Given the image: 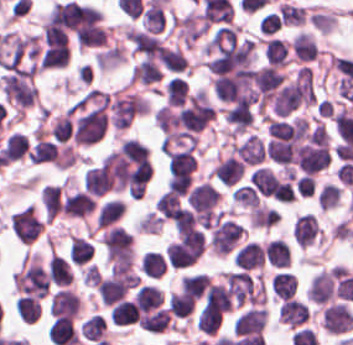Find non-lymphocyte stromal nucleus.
<instances>
[{
    "label": "non-lymphocyte stromal nucleus",
    "instance_id": "3746e769",
    "mask_svg": "<svg viewBox=\"0 0 353 345\" xmlns=\"http://www.w3.org/2000/svg\"><path fill=\"white\" fill-rule=\"evenodd\" d=\"M321 327L330 335H341L353 330V315L345 304H331L322 310Z\"/></svg>",
    "mask_w": 353,
    "mask_h": 345
},
{
    "label": "non-lymphocyte stromal nucleus",
    "instance_id": "68dcb563",
    "mask_svg": "<svg viewBox=\"0 0 353 345\" xmlns=\"http://www.w3.org/2000/svg\"><path fill=\"white\" fill-rule=\"evenodd\" d=\"M270 286L277 298L286 300L295 293L296 277L286 271H279L273 274Z\"/></svg>",
    "mask_w": 353,
    "mask_h": 345
},
{
    "label": "non-lymphocyte stromal nucleus",
    "instance_id": "8bb88acc",
    "mask_svg": "<svg viewBox=\"0 0 353 345\" xmlns=\"http://www.w3.org/2000/svg\"><path fill=\"white\" fill-rule=\"evenodd\" d=\"M109 321L117 326H126L137 322V309L130 299H123L114 305Z\"/></svg>",
    "mask_w": 353,
    "mask_h": 345
},
{
    "label": "non-lymphocyte stromal nucleus",
    "instance_id": "a72fc3eb",
    "mask_svg": "<svg viewBox=\"0 0 353 345\" xmlns=\"http://www.w3.org/2000/svg\"><path fill=\"white\" fill-rule=\"evenodd\" d=\"M14 236L21 243H32L40 234L42 220L35 206H27L10 217Z\"/></svg>",
    "mask_w": 353,
    "mask_h": 345
},
{
    "label": "non-lymphocyte stromal nucleus",
    "instance_id": "c95308c0",
    "mask_svg": "<svg viewBox=\"0 0 353 345\" xmlns=\"http://www.w3.org/2000/svg\"><path fill=\"white\" fill-rule=\"evenodd\" d=\"M208 281L209 276L202 273L185 274L181 278L180 289L197 300L207 288Z\"/></svg>",
    "mask_w": 353,
    "mask_h": 345
},
{
    "label": "non-lymphocyte stromal nucleus",
    "instance_id": "6412c185",
    "mask_svg": "<svg viewBox=\"0 0 353 345\" xmlns=\"http://www.w3.org/2000/svg\"><path fill=\"white\" fill-rule=\"evenodd\" d=\"M279 179L273 171L264 166H257L249 173V185L262 196H275Z\"/></svg>",
    "mask_w": 353,
    "mask_h": 345
},
{
    "label": "non-lymphocyte stromal nucleus",
    "instance_id": "0ceb972a",
    "mask_svg": "<svg viewBox=\"0 0 353 345\" xmlns=\"http://www.w3.org/2000/svg\"><path fill=\"white\" fill-rule=\"evenodd\" d=\"M192 210H212L219 199L218 190L206 182H202L187 194Z\"/></svg>",
    "mask_w": 353,
    "mask_h": 345
},
{
    "label": "non-lymphocyte stromal nucleus",
    "instance_id": "e25f4989",
    "mask_svg": "<svg viewBox=\"0 0 353 345\" xmlns=\"http://www.w3.org/2000/svg\"><path fill=\"white\" fill-rule=\"evenodd\" d=\"M162 294L154 285H144L134 293L133 303L142 311L149 312L159 308Z\"/></svg>",
    "mask_w": 353,
    "mask_h": 345
},
{
    "label": "non-lymphocyte stromal nucleus",
    "instance_id": "d581f26b",
    "mask_svg": "<svg viewBox=\"0 0 353 345\" xmlns=\"http://www.w3.org/2000/svg\"><path fill=\"white\" fill-rule=\"evenodd\" d=\"M94 246L85 238L71 235L70 260L74 264H83L88 262Z\"/></svg>",
    "mask_w": 353,
    "mask_h": 345
},
{
    "label": "non-lymphocyte stromal nucleus",
    "instance_id": "8191ca87",
    "mask_svg": "<svg viewBox=\"0 0 353 345\" xmlns=\"http://www.w3.org/2000/svg\"><path fill=\"white\" fill-rule=\"evenodd\" d=\"M154 208L161 218L175 222L180 209V199L178 195L167 189L159 195Z\"/></svg>",
    "mask_w": 353,
    "mask_h": 345
},
{
    "label": "non-lymphocyte stromal nucleus",
    "instance_id": "a21756e0",
    "mask_svg": "<svg viewBox=\"0 0 353 345\" xmlns=\"http://www.w3.org/2000/svg\"><path fill=\"white\" fill-rule=\"evenodd\" d=\"M48 278L57 284L72 282V271L65 259L52 252L47 265Z\"/></svg>",
    "mask_w": 353,
    "mask_h": 345
},
{
    "label": "non-lymphocyte stromal nucleus",
    "instance_id": "36bbc26a",
    "mask_svg": "<svg viewBox=\"0 0 353 345\" xmlns=\"http://www.w3.org/2000/svg\"><path fill=\"white\" fill-rule=\"evenodd\" d=\"M40 299L26 295H19L16 302L15 311L24 324H33L41 316Z\"/></svg>",
    "mask_w": 353,
    "mask_h": 345
},
{
    "label": "non-lymphocyte stromal nucleus",
    "instance_id": "bbfbcbc0",
    "mask_svg": "<svg viewBox=\"0 0 353 345\" xmlns=\"http://www.w3.org/2000/svg\"><path fill=\"white\" fill-rule=\"evenodd\" d=\"M244 168L238 158L227 156L212 169L211 174L222 184H235L243 176Z\"/></svg>",
    "mask_w": 353,
    "mask_h": 345
},
{
    "label": "non-lymphocyte stromal nucleus",
    "instance_id": "7de87821",
    "mask_svg": "<svg viewBox=\"0 0 353 345\" xmlns=\"http://www.w3.org/2000/svg\"><path fill=\"white\" fill-rule=\"evenodd\" d=\"M260 35H271L280 28L279 16L269 12L258 20Z\"/></svg>",
    "mask_w": 353,
    "mask_h": 345
},
{
    "label": "non-lymphocyte stromal nucleus",
    "instance_id": "4191e051",
    "mask_svg": "<svg viewBox=\"0 0 353 345\" xmlns=\"http://www.w3.org/2000/svg\"><path fill=\"white\" fill-rule=\"evenodd\" d=\"M28 149V140L23 133L12 132L5 140L1 156L8 161H15L22 158Z\"/></svg>",
    "mask_w": 353,
    "mask_h": 345
},
{
    "label": "non-lymphocyte stromal nucleus",
    "instance_id": "2a442b8e",
    "mask_svg": "<svg viewBox=\"0 0 353 345\" xmlns=\"http://www.w3.org/2000/svg\"><path fill=\"white\" fill-rule=\"evenodd\" d=\"M106 324L103 315L93 314L83 321L79 334L84 340L100 341L104 340Z\"/></svg>",
    "mask_w": 353,
    "mask_h": 345
},
{
    "label": "non-lymphocyte stromal nucleus",
    "instance_id": "616ff342",
    "mask_svg": "<svg viewBox=\"0 0 353 345\" xmlns=\"http://www.w3.org/2000/svg\"><path fill=\"white\" fill-rule=\"evenodd\" d=\"M320 227L314 215H300L294 223L291 235L298 247H308L314 243Z\"/></svg>",
    "mask_w": 353,
    "mask_h": 345
},
{
    "label": "non-lymphocyte stromal nucleus",
    "instance_id": "0962c487",
    "mask_svg": "<svg viewBox=\"0 0 353 345\" xmlns=\"http://www.w3.org/2000/svg\"><path fill=\"white\" fill-rule=\"evenodd\" d=\"M125 208L124 201L118 198L105 200L98 209L96 224L97 227H108L123 215Z\"/></svg>",
    "mask_w": 353,
    "mask_h": 345
},
{
    "label": "non-lymphocyte stromal nucleus",
    "instance_id": "0f0694cc",
    "mask_svg": "<svg viewBox=\"0 0 353 345\" xmlns=\"http://www.w3.org/2000/svg\"><path fill=\"white\" fill-rule=\"evenodd\" d=\"M139 266L141 273L151 278H160L165 272L166 261L157 251H144Z\"/></svg>",
    "mask_w": 353,
    "mask_h": 345
},
{
    "label": "non-lymphocyte stromal nucleus",
    "instance_id": "dd21d789",
    "mask_svg": "<svg viewBox=\"0 0 353 345\" xmlns=\"http://www.w3.org/2000/svg\"><path fill=\"white\" fill-rule=\"evenodd\" d=\"M340 268L332 267L311 278L306 289V298L315 304H325L334 298L337 291Z\"/></svg>",
    "mask_w": 353,
    "mask_h": 345
},
{
    "label": "non-lymphocyte stromal nucleus",
    "instance_id": "7c5642bf",
    "mask_svg": "<svg viewBox=\"0 0 353 345\" xmlns=\"http://www.w3.org/2000/svg\"><path fill=\"white\" fill-rule=\"evenodd\" d=\"M94 208V196L84 190H77L63 200L61 213L72 218H84Z\"/></svg>",
    "mask_w": 353,
    "mask_h": 345
},
{
    "label": "non-lymphocyte stromal nucleus",
    "instance_id": "fc2b8d12",
    "mask_svg": "<svg viewBox=\"0 0 353 345\" xmlns=\"http://www.w3.org/2000/svg\"><path fill=\"white\" fill-rule=\"evenodd\" d=\"M266 322V310L260 307L248 308L235 319L232 330L234 336H247L261 332Z\"/></svg>",
    "mask_w": 353,
    "mask_h": 345
},
{
    "label": "non-lymphocyte stromal nucleus",
    "instance_id": "c2bb4b8c",
    "mask_svg": "<svg viewBox=\"0 0 353 345\" xmlns=\"http://www.w3.org/2000/svg\"><path fill=\"white\" fill-rule=\"evenodd\" d=\"M340 197V186L325 183L318 192L316 199L320 210H328L338 203Z\"/></svg>",
    "mask_w": 353,
    "mask_h": 345
},
{
    "label": "non-lymphocyte stromal nucleus",
    "instance_id": "916006d4",
    "mask_svg": "<svg viewBox=\"0 0 353 345\" xmlns=\"http://www.w3.org/2000/svg\"><path fill=\"white\" fill-rule=\"evenodd\" d=\"M270 265L286 268L290 265V251L288 245L279 238L268 241L264 251Z\"/></svg>",
    "mask_w": 353,
    "mask_h": 345
},
{
    "label": "non-lymphocyte stromal nucleus",
    "instance_id": "fcafb8cc",
    "mask_svg": "<svg viewBox=\"0 0 353 345\" xmlns=\"http://www.w3.org/2000/svg\"><path fill=\"white\" fill-rule=\"evenodd\" d=\"M194 302V298L181 290L171 293L167 309L174 316L186 317L192 311Z\"/></svg>",
    "mask_w": 353,
    "mask_h": 345
},
{
    "label": "non-lymphocyte stromal nucleus",
    "instance_id": "2ac0efb1",
    "mask_svg": "<svg viewBox=\"0 0 353 345\" xmlns=\"http://www.w3.org/2000/svg\"><path fill=\"white\" fill-rule=\"evenodd\" d=\"M79 309V300L72 289L60 288L51 297L50 314L52 316L73 318Z\"/></svg>",
    "mask_w": 353,
    "mask_h": 345
},
{
    "label": "non-lymphocyte stromal nucleus",
    "instance_id": "b5412eef",
    "mask_svg": "<svg viewBox=\"0 0 353 345\" xmlns=\"http://www.w3.org/2000/svg\"><path fill=\"white\" fill-rule=\"evenodd\" d=\"M265 60L273 67H283L288 63L286 44L283 39L269 37L265 41Z\"/></svg>",
    "mask_w": 353,
    "mask_h": 345
},
{
    "label": "non-lymphocyte stromal nucleus",
    "instance_id": "81446118",
    "mask_svg": "<svg viewBox=\"0 0 353 345\" xmlns=\"http://www.w3.org/2000/svg\"><path fill=\"white\" fill-rule=\"evenodd\" d=\"M233 151L244 164L255 165L265 158L268 149L257 134H249Z\"/></svg>",
    "mask_w": 353,
    "mask_h": 345
},
{
    "label": "non-lymphocyte stromal nucleus",
    "instance_id": "9d01c50a",
    "mask_svg": "<svg viewBox=\"0 0 353 345\" xmlns=\"http://www.w3.org/2000/svg\"><path fill=\"white\" fill-rule=\"evenodd\" d=\"M264 260V250L251 240L239 248L233 258V264L248 272L263 267Z\"/></svg>",
    "mask_w": 353,
    "mask_h": 345
},
{
    "label": "non-lymphocyte stromal nucleus",
    "instance_id": "51effc4e",
    "mask_svg": "<svg viewBox=\"0 0 353 345\" xmlns=\"http://www.w3.org/2000/svg\"><path fill=\"white\" fill-rule=\"evenodd\" d=\"M308 310L304 302L290 298L280 304L278 320L289 327H297L305 321Z\"/></svg>",
    "mask_w": 353,
    "mask_h": 345
}]
</instances>
